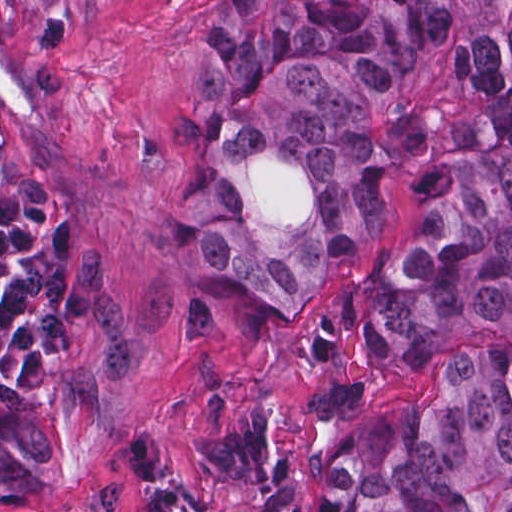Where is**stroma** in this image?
<instances>
[{
	"mask_svg": "<svg viewBox=\"0 0 512 512\" xmlns=\"http://www.w3.org/2000/svg\"><path fill=\"white\" fill-rule=\"evenodd\" d=\"M214 0H0V137L29 181L75 216L125 333L127 405L105 422L50 418V488L0 512H130L171 489L189 512H326L317 465L368 414L434 386L463 356L512 355V334L430 338L403 359L334 344L348 311L424 218L420 184L458 83V28L371 99L384 221L354 268L331 263L308 300L284 303L205 251L207 159L178 137V108L216 39ZM512 6V0H510ZM248 184L266 226L317 210L318 178L275 147Z\"/></svg>",
	"mask_w": 512,
	"mask_h": 512,
	"instance_id": "1",
	"label": "stroma"
}]
</instances>
